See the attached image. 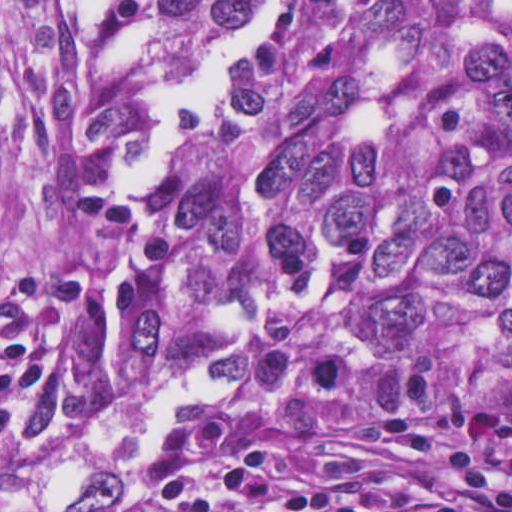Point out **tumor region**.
<instances>
[{
    "label": "tumor region",
    "instance_id": "obj_1",
    "mask_svg": "<svg viewBox=\"0 0 512 512\" xmlns=\"http://www.w3.org/2000/svg\"><path fill=\"white\" fill-rule=\"evenodd\" d=\"M320 286L361 409L512 411V0H1V512L280 398Z\"/></svg>",
    "mask_w": 512,
    "mask_h": 512
}]
</instances>
